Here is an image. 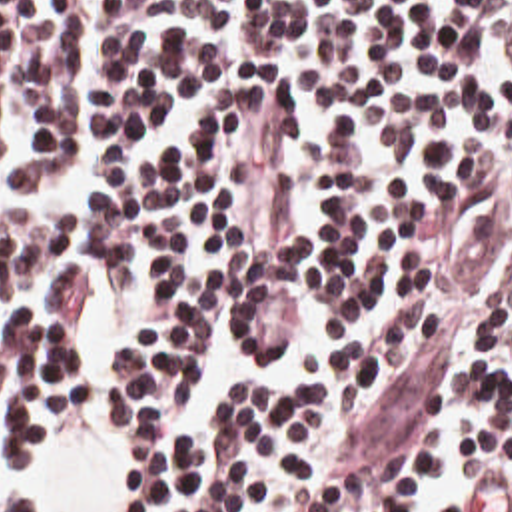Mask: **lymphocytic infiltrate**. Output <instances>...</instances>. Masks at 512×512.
Returning a JSON list of instances; mask_svg holds the SVG:
<instances>
[{"instance_id": "lymphocytic-infiltrate-1", "label": "lymphocytic infiltrate", "mask_w": 512, "mask_h": 512, "mask_svg": "<svg viewBox=\"0 0 512 512\" xmlns=\"http://www.w3.org/2000/svg\"><path fill=\"white\" fill-rule=\"evenodd\" d=\"M104 266L124 512H420L448 414L512 512V0H0L11 460L84 388ZM0 512H45L5 492Z\"/></svg>"}]
</instances>
